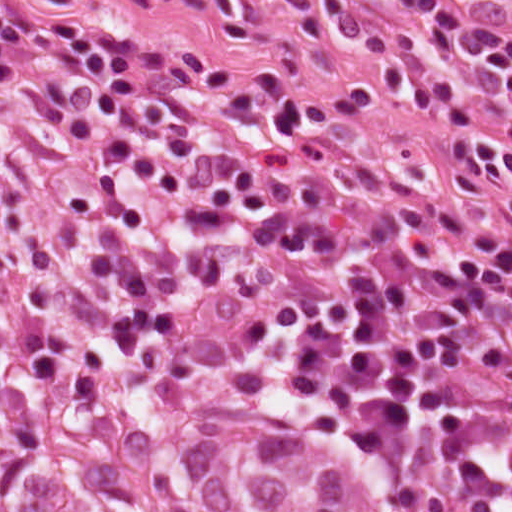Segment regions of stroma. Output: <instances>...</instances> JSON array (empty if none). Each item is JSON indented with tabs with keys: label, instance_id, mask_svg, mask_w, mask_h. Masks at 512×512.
Here are the masks:
<instances>
[{
	"label": "stroma",
	"instance_id": "obj_1",
	"mask_svg": "<svg viewBox=\"0 0 512 512\" xmlns=\"http://www.w3.org/2000/svg\"><path fill=\"white\" fill-rule=\"evenodd\" d=\"M512 35V0H454ZM367 26L414 28L398 0H347ZM83 11L115 27L152 33L177 55L230 79L296 102L313 128L366 159L402 191L446 208L512 262V217L496 194L467 203L450 183V135L485 129L512 139L510 97L490 68L452 48L438 63L457 95L421 109L389 91L367 112H345L340 87L382 75L379 57L338 29L327 0H82ZM36 68L0 72V332L89 327L56 291L27 240L34 166L58 159L54 138L30 100Z\"/></svg>",
	"mask_w": 512,
	"mask_h": 512
}]
</instances>
